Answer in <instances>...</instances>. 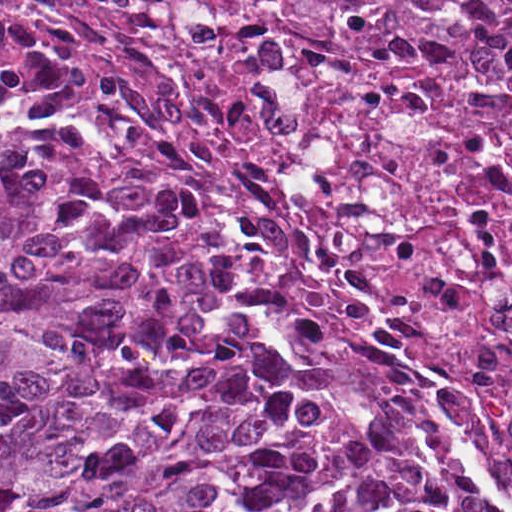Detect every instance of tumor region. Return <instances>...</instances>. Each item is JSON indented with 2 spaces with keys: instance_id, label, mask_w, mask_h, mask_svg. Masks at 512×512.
<instances>
[{
  "instance_id": "1",
  "label": "tumor region",
  "mask_w": 512,
  "mask_h": 512,
  "mask_svg": "<svg viewBox=\"0 0 512 512\" xmlns=\"http://www.w3.org/2000/svg\"><path fill=\"white\" fill-rule=\"evenodd\" d=\"M412 436L263 339L67 125L0 112V512H437Z\"/></svg>"
}]
</instances>
